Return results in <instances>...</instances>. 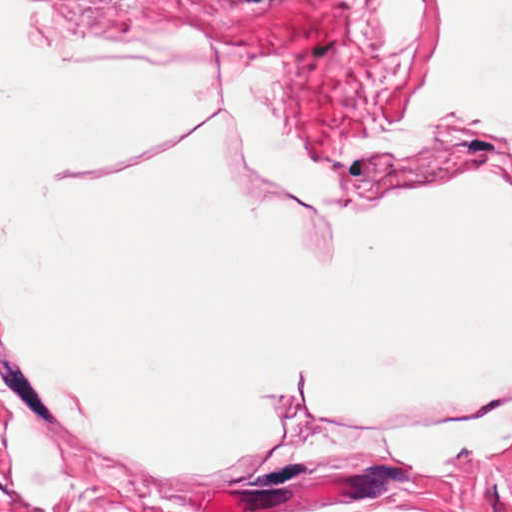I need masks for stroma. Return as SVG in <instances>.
<instances>
[{
  "label": "stroma",
  "mask_w": 512,
  "mask_h": 512,
  "mask_svg": "<svg viewBox=\"0 0 512 512\" xmlns=\"http://www.w3.org/2000/svg\"><path fill=\"white\" fill-rule=\"evenodd\" d=\"M0 512H512V446L470 474L372 466L293 442L240 480L153 476L0 361Z\"/></svg>",
  "instance_id": "35a3bbf8"
}]
</instances>
